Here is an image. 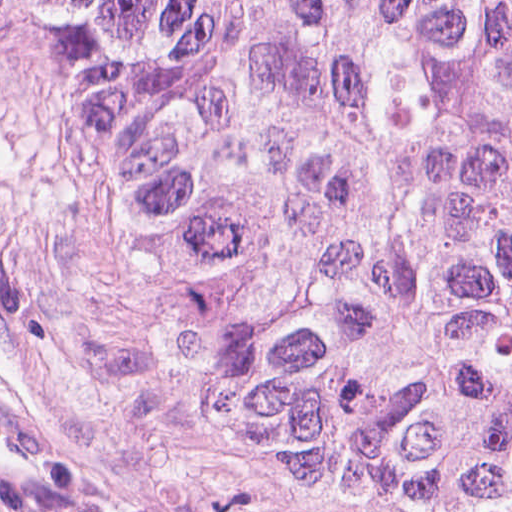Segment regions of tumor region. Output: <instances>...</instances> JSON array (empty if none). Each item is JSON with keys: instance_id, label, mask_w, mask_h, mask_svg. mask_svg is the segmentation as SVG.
Returning <instances> with one entry per match:
<instances>
[{"instance_id": "e687c5a6", "label": "tumor region", "mask_w": 512, "mask_h": 512, "mask_svg": "<svg viewBox=\"0 0 512 512\" xmlns=\"http://www.w3.org/2000/svg\"><path fill=\"white\" fill-rule=\"evenodd\" d=\"M167 376L356 512H512V0H0Z\"/></svg>"}]
</instances>
